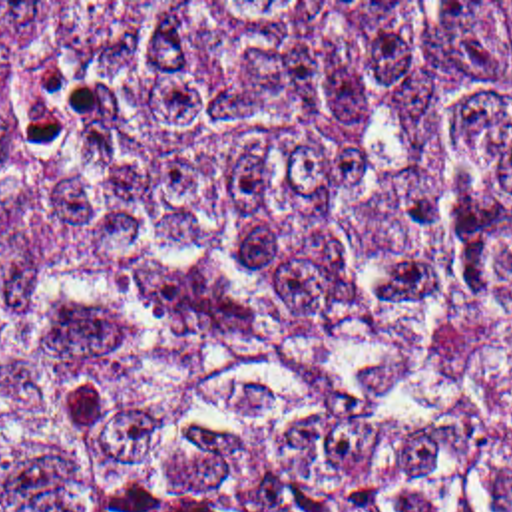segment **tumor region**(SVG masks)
I'll return each mask as SVG.
<instances>
[{"label": "tumor region", "mask_w": 512, "mask_h": 512, "mask_svg": "<svg viewBox=\"0 0 512 512\" xmlns=\"http://www.w3.org/2000/svg\"><path fill=\"white\" fill-rule=\"evenodd\" d=\"M0 512H512V2H0Z\"/></svg>", "instance_id": "1"}]
</instances>
